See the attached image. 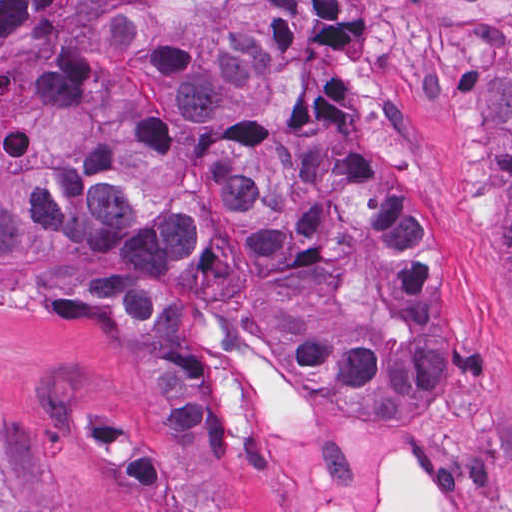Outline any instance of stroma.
Here are the masks:
<instances>
[{"instance_id":"35a3bbf8","label":"stroma","mask_w":512,"mask_h":512,"mask_svg":"<svg viewBox=\"0 0 512 512\" xmlns=\"http://www.w3.org/2000/svg\"><path fill=\"white\" fill-rule=\"evenodd\" d=\"M112 1V0H111ZM241 1V0H230ZM364 38L349 79L356 129H330L267 65V0L257 33L282 123L323 148L378 164L424 215L450 307L452 384L424 417L368 425L334 411L272 429L246 454L229 445L238 512H375L389 463L414 461L444 512H512V334L485 211L488 130L471 97L512 57V0H350ZM181 299L206 330L229 315ZM292 372V371H291ZM160 452L128 333L97 297L0 272V486L39 512H145L69 437L72 415Z\"/></svg>"}]
</instances>
